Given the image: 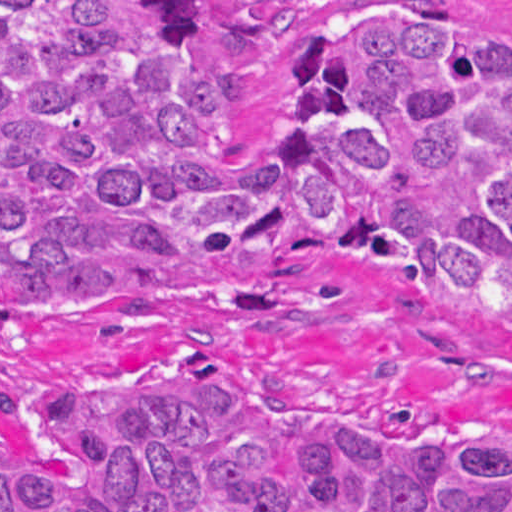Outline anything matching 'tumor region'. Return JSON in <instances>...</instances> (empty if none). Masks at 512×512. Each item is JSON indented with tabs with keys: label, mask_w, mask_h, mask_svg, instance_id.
I'll return each instance as SVG.
<instances>
[{
	"label": "tumor region",
	"mask_w": 512,
	"mask_h": 512,
	"mask_svg": "<svg viewBox=\"0 0 512 512\" xmlns=\"http://www.w3.org/2000/svg\"><path fill=\"white\" fill-rule=\"evenodd\" d=\"M288 1H1V310L249 263L375 260L512 326V35L460 1H329L268 116L233 107ZM1 512H512V434L297 428L168 356L3 400Z\"/></svg>",
	"instance_id": "1"
}]
</instances>
